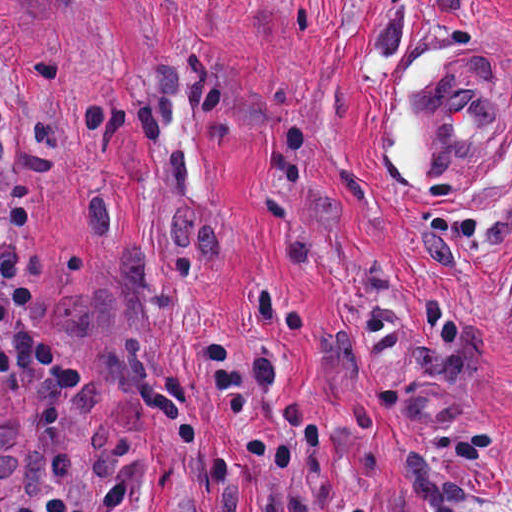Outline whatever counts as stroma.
<instances>
[{
	"instance_id": "35a3bbf8",
	"label": "stroma",
	"mask_w": 512,
	"mask_h": 512,
	"mask_svg": "<svg viewBox=\"0 0 512 512\" xmlns=\"http://www.w3.org/2000/svg\"><path fill=\"white\" fill-rule=\"evenodd\" d=\"M467 44L512 66V0H0V195L83 371L0 379V512H512V108L430 194L394 161Z\"/></svg>"
}]
</instances>
